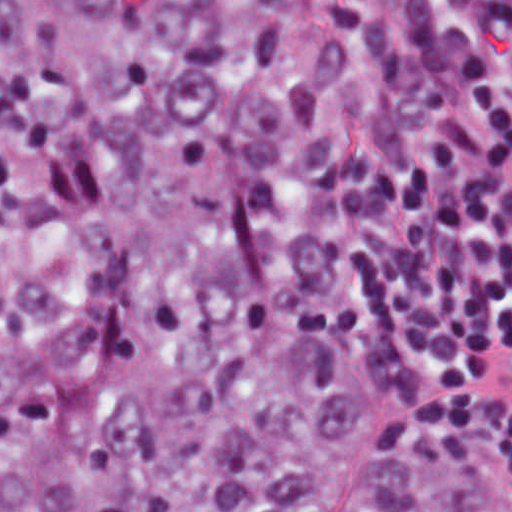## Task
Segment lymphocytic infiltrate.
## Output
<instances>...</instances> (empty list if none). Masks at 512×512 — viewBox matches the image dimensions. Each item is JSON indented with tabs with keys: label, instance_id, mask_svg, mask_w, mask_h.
<instances>
[{
	"label": "lymphocytic infiltrate",
	"instance_id": "1",
	"mask_svg": "<svg viewBox=\"0 0 512 512\" xmlns=\"http://www.w3.org/2000/svg\"><path fill=\"white\" fill-rule=\"evenodd\" d=\"M512 0H373L336 103V259L512 486Z\"/></svg>",
	"mask_w": 512,
	"mask_h": 512
}]
</instances>
